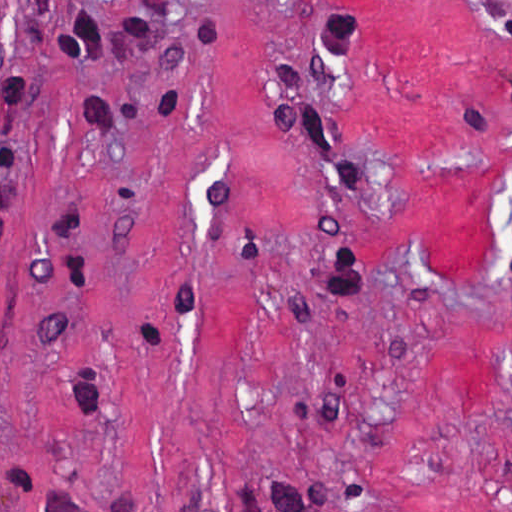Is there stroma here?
Returning a JSON list of instances; mask_svg holds the SVG:
<instances>
[{
    "label": "stroma",
    "instance_id": "35a3bbf8",
    "mask_svg": "<svg viewBox=\"0 0 512 512\" xmlns=\"http://www.w3.org/2000/svg\"><path fill=\"white\" fill-rule=\"evenodd\" d=\"M512 0H0V512H512Z\"/></svg>",
    "mask_w": 512,
    "mask_h": 512
}]
</instances>
